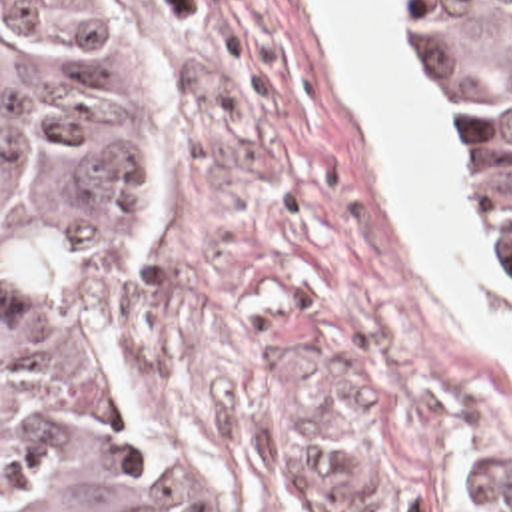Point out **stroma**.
<instances>
[{
	"mask_svg": "<svg viewBox=\"0 0 512 512\" xmlns=\"http://www.w3.org/2000/svg\"><path fill=\"white\" fill-rule=\"evenodd\" d=\"M116 3L150 99L146 221L66 303L82 389L188 512H512V361L395 215L313 0ZM489 247L512 303L491 213Z\"/></svg>",
	"mask_w": 512,
	"mask_h": 512,
	"instance_id": "stroma-1",
	"label": "stroma"
}]
</instances>
